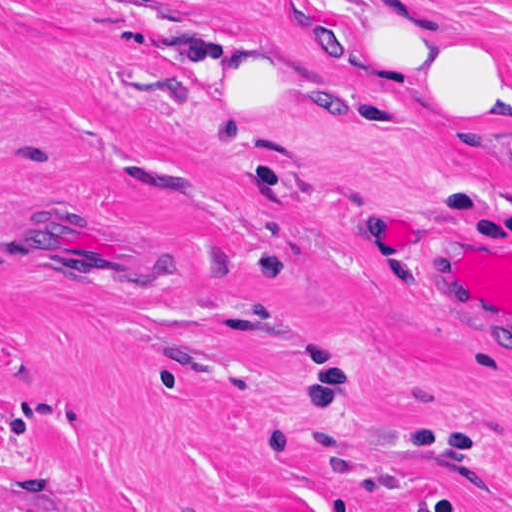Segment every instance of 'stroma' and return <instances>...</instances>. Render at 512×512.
<instances>
[{"instance_id":"stroma-1","label":"stroma","mask_w":512,"mask_h":512,"mask_svg":"<svg viewBox=\"0 0 512 512\" xmlns=\"http://www.w3.org/2000/svg\"><path fill=\"white\" fill-rule=\"evenodd\" d=\"M365 2L0 0V512H512V317L427 270L512 157L350 100Z\"/></svg>"}]
</instances>
